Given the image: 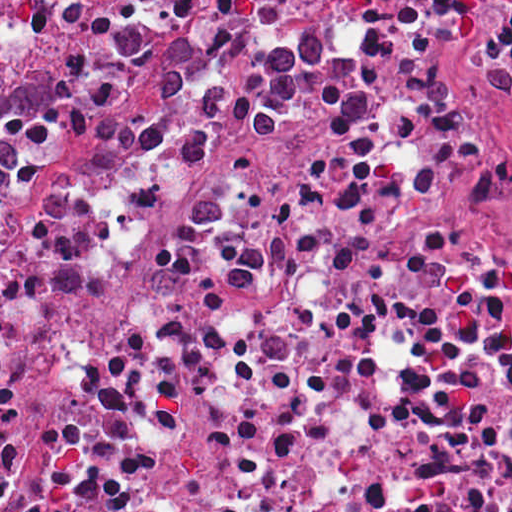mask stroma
Returning a JSON list of instances; mask_svg holds the SVG:
<instances>
[{
	"label": "stroma",
	"mask_w": 512,
	"mask_h": 512,
	"mask_svg": "<svg viewBox=\"0 0 512 512\" xmlns=\"http://www.w3.org/2000/svg\"><path fill=\"white\" fill-rule=\"evenodd\" d=\"M0 81H56V103L44 112L7 117L1 131L14 166L0 184V200L44 144L70 132L113 89L98 73H26L10 62V41L0 35Z\"/></svg>",
	"instance_id": "stroma-1"
}]
</instances>
